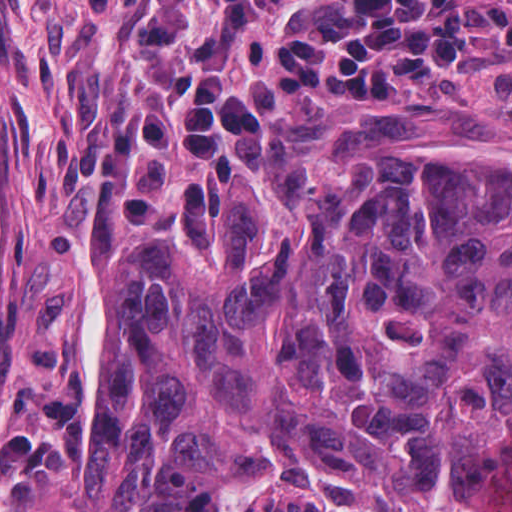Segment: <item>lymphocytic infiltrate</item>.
<instances>
[{
  "mask_svg": "<svg viewBox=\"0 0 512 512\" xmlns=\"http://www.w3.org/2000/svg\"><path fill=\"white\" fill-rule=\"evenodd\" d=\"M115 19L119 105L72 164L112 217L157 206L169 155L236 162L282 90L424 99L492 34L512 41V0H84Z\"/></svg>",
  "mask_w": 512,
  "mask_h": 512,
  "instance_id": "obj_1",
  "label": "lymphocytic infiltrate"
}]
</instances>
